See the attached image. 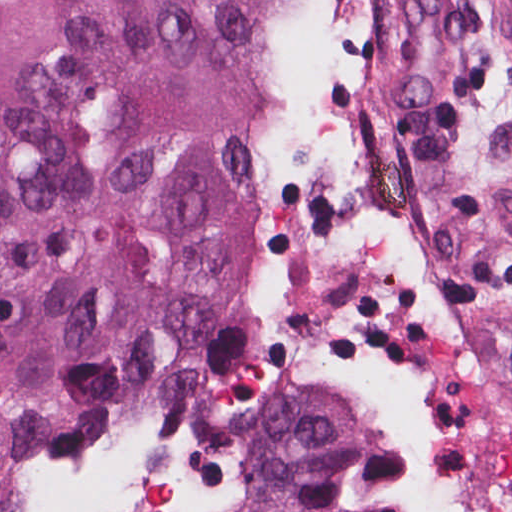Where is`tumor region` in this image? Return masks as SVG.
Segmentation results:
<instances>
[{
  "label": "tumor region",
  "mask_w": 512,
  "mask_h": 512,
  "mask_svg": "<svg viewBox=\"0 0 512 512\" xmlns=\"http://www.w3.org/2000/svg\"><path fill=\"white\" fill-rule=\"evenodd\" d=\"M302 0H0V501L52 512L252 252ZM381 405H301L246 512H381Z\"/></svg>",
  "instance_id": "1"
}]
</instances>
